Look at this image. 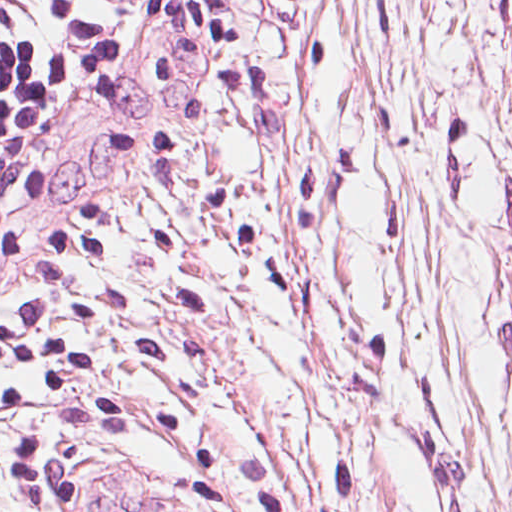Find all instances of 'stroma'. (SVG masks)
<instances>
[{
  "label": "stroma",
  "instance_id": "1",
  "mask_svg": "<svg viewBox=\"0 0 512 512\" xmlns=\"http://www.w3.org/2000/svg\"><path fill=\"white\" fill-rule=\"evenodd\" d=\"M0 512H512V0H152L0 210Z\"/></svg>",
  "mask_w": 512,
  "mask_h": 512
}]
</instances>
